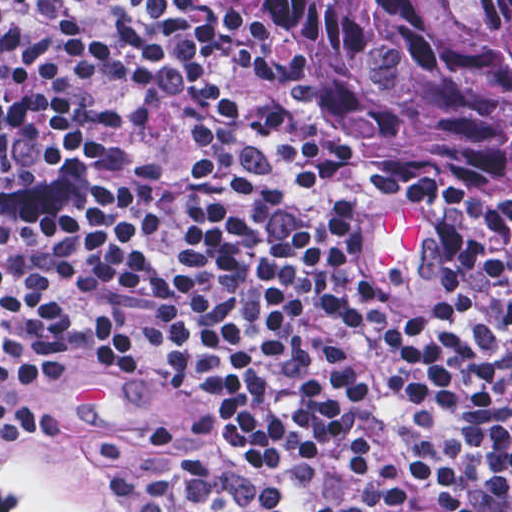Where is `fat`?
Returning a JSON list of instances; mask_svg holds the SVG:
<instances>
[{"instance_id":"53f6f03d","label":"fat","mask_w":512,"mask_h":512,"mask_svg":"<svg viewBox=\"0 0 512 512\" xmlns=\"http://www.w3.org/2000/svg\"><path fill=\"white\" fill-rule=\"evenodd\" d=\"M430 227L406 209L381 211L371 242V267L375 276H388ZM0 480L31 506L53 512H83L47 478L33 471L0 444Z\"/></svg>"}]
</instances>
